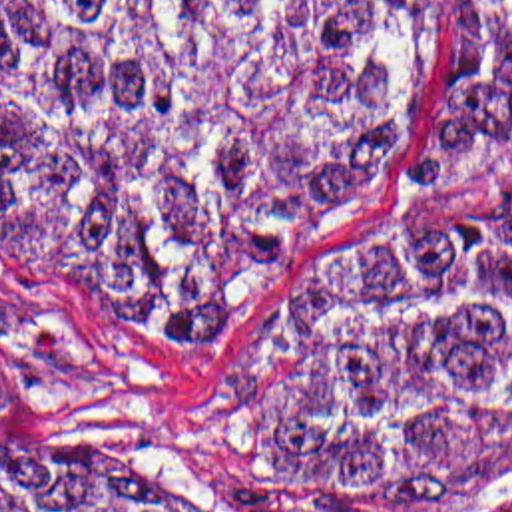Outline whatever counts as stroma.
<instances>
[{"label":"stroma","mask_w":512,"mask_h":512,"mask_svg":"<svg viewBox=\"0 0 512 512\" xmlns=\"http://www.w3.org/2000/svg\"><path fill=\"white\" fill-rule=\"evenodd\" d=\"M444 4L424 0L409 107L307 276L347 271L381 215L409 191ZM229 348L164 320L64 296L0 255V352L28 384L16 418L0 428V484L108 512H293L187 424L183 388Z\"/></svg>","instance_id":"stroma-1"}]
</instances>
